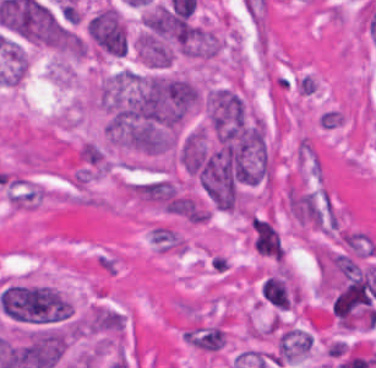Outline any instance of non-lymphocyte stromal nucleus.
<instances>
[{
  "label": "non-lymphocyte stromal nucleus",
  "instance_id": "obj_1",
  "mask_svg": "<svg viewBox=\"0 0 376 368\" xmlns=\"http://www.w3.org/2000/svg\"><path fill=\"white\" fill-rule=\"evenodd\" d=\"M248 231L250 244L255 252L282 262L285 245L274 221L269 216L255 214L249 216Z\"/></svg>",
  "mask_w": 376,
  "mask_h": 368
},
{
  "label": "non-lymphocyte stromal nucleus",
  "instance_id": "obj_2",
  "mask_svg": "<svg viewBox=\"0 0 376 368\" xmlns=\"http://www.w3.org/2000/svg\"><path fill=\"white\" fill-rule=\"evenodd\" d=\"M149 239L158 252H183L186 246L183 238L168 226L155 225Z\"/></svg>",
  "mask_w": 376,
  "mask_h": 368
}]
</instances>
